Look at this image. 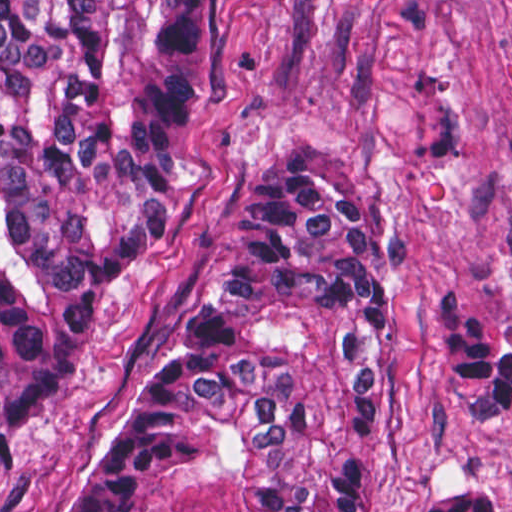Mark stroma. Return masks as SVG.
Instances as JSON below:
<instances>
[{"label":"stroma","instance_id":"obj_1","mask_svg":"<svg viewBox=\"0 0 512 512\" xmlns=\"http://www.w3.org/2000/svg\"><path fill=\"white\" fill-rule=\"evenodd\" d=\"M186 207L111 284L68 389L0 464V512H69L164 368L280 145L364 182L390 276L360 512H429L480 483L483 402L444 311L512 344V0H195ZM512 512V394L487 422Z\"/></svg>","mask_w":512,"mask_h":512}]
</instances>
